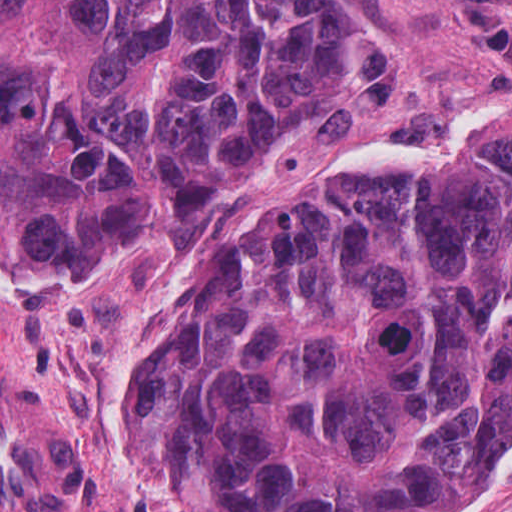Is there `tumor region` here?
Instances as JSON below:
<instances>
[{
  "label": "tumor region",
  "mask_w": 512,
  "mask_h": 512,
  "mask_svg": "<svg viewBox=\"0 0 512 512\" xmlns=\"http://www.w3.org/2000/svg\"><path fill=\"white\" fill-rule=\"evenodd\" d=\"M367 0H1V283L172 251L340 93ZM198 512H453L512 437V114L199 258L111 414Z\"/></svg>",
  "instance_id": "obj_1"
}]
</instances>
